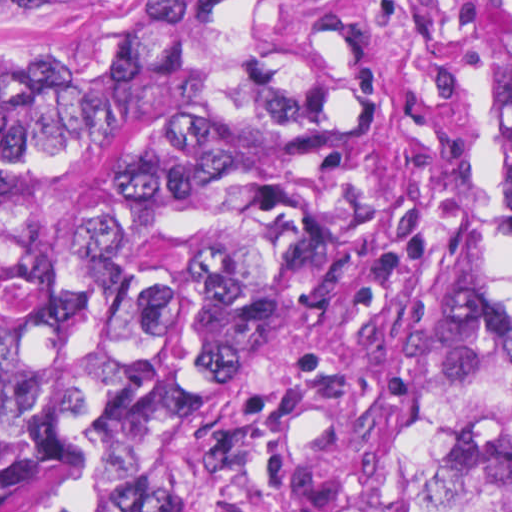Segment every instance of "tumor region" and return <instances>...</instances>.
Wrapping results in <instances>:
<instances>
[{
  "label": "tumor region",
  "instance_id": "obj_1",
  "mask_svg": "<svg viewBox=\"0 0 512 512\" xmlns=\"http://www.w3.org/2000/svg\"><path fill=\"white\" fill-rule=\"evenodd\" d=\"M71 16L1 70V512H512V224L299 76L258 0ZM493 197L512 211V0Z\"/></svg>",
  "mask_w": 512,
  "mask_h": 512
}]
</instances>
